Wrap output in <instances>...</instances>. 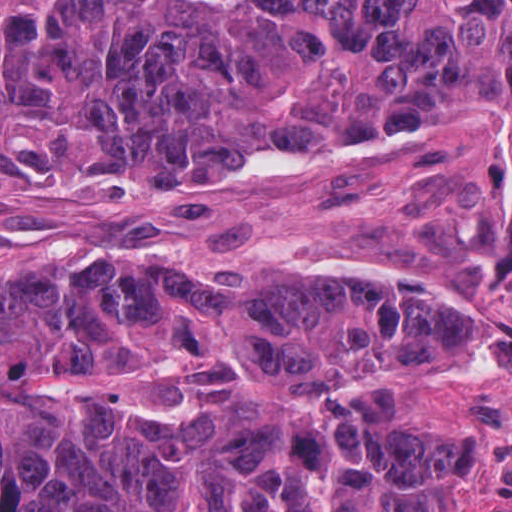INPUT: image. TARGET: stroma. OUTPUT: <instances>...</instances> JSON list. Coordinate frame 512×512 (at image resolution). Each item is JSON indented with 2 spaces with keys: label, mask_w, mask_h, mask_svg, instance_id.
<instances>
[{
  "label": "stroma",
  "mask_w": 512,
  "mask_h": 512,
  "mask_svg": "<svg viewBox=\"0 0 512 512\" xmlns=\"http://www.w3.org/2000/svg\"><path fill=\"white\" fill-rule=\"evenodd\" d=\"M314 269L434 279L471 303L470 351L422 365L390 397L403 433L456 441L446 512H512V150L497 139L426 136L150 236L0 225L2 293L59 278L271 283ZM0 370L54 405L106 407L153 432L188 426L211 399L330 407L354 390L3 338Z\"/></svg>",
  "instance_id": "35a3bbf8"
}]
</instances>
